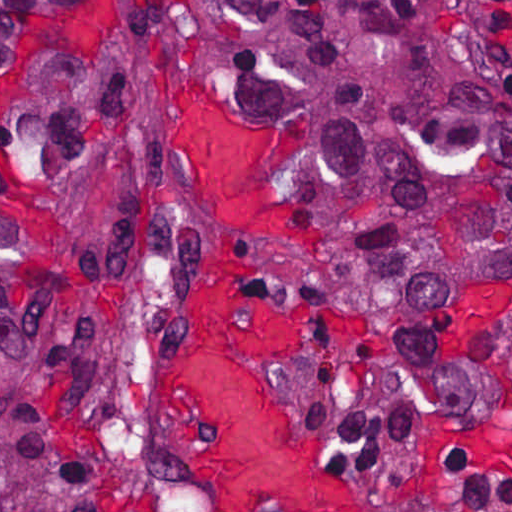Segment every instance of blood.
<instances>
[{
    "mask_svg": "<svg viewBox=\"0 0 512 512\" xmlns=\"http://www.w3.org/2000/svg\"><path fill=\"white\" fill-rule=\"evenodd\" d=\"M180 102L174 145L196 165L198 192L225 240L182 320L164 432L213 512H265L271 503L284 512H357L325 438L300 419L261 362L300 363L308 353L311 320L269 295L253 254L259 243L308 251L322 236L288 203L297 141L184 94L176 112Z\"/></svg>",
    "mask_w": 512,
    "mask_h": 512,
    "instance_id": "1",
    "label": "blood"
}]
</instances>
